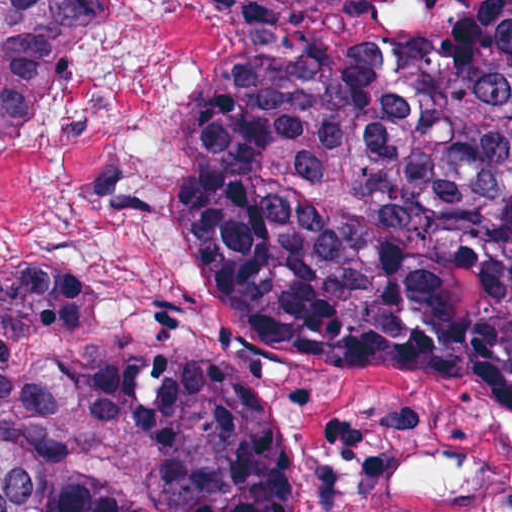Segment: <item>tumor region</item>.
Returning a JSON list of instances; mask_svg holds the SVG:
<instances>
[{
    "label": "tumor region",
    "mask_w": 512,
    "mask_h": 512,
    "mask_svg": "<svg viewBox=\"0 0 512 512\" xmlns=\"http://www.w3.org/2000/svg\"><path fill=\"white\" fill-rule=\"evenodd\" d=\"M94 1H0V133ZM191 230L255 330L320 365L512 386V1H364L217 37ZM293 512L282 429L233 369L137 355L62 277L0 279V512Z\"/></svg>",
    "instance_id": "1"
}]
</instances>
